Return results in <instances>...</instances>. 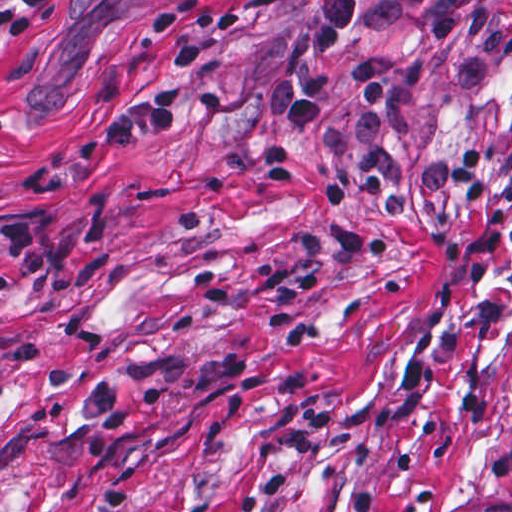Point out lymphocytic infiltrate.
Instances as JSON below:
<instances>
[{
	"instance_id": "lymphocytic-infiltrate-1",
	"label": "lymphocytic infiltrate",
	"mask_w": 512,
	"mask_h": 512,
	"mask_svg": "<svg viewBox=\"0 0 512 512\" xmlns=\"http://www.w3.org/2000/svg\"><path fill=\"white\" fill-rule=\"evenodd\" d=\"M512 0H308L279 58L264 76V108L287 135L312 129L338 42L365 27L417 25V40L370 54L353 79L357 113L324 148L310 189L317 203H367L398 215L416 195L450 197L466 209L485 202L478 154L442 149L420 154L399 146L404 91L433 74L450 41L466 44L465 78L475 87L512 52ZM246 27L242 9H207L185 0L151 18L150 29L172 43L170 78L152 97L113 116L69 158L38 180V190L74 186L96 161L179 131L189 108L217 116V88L184 89L206 52L188 34L223 45ZM52 247L33 217L0 224V299L32 292L47 280Z\"/></svg>"
}]
</instances>
